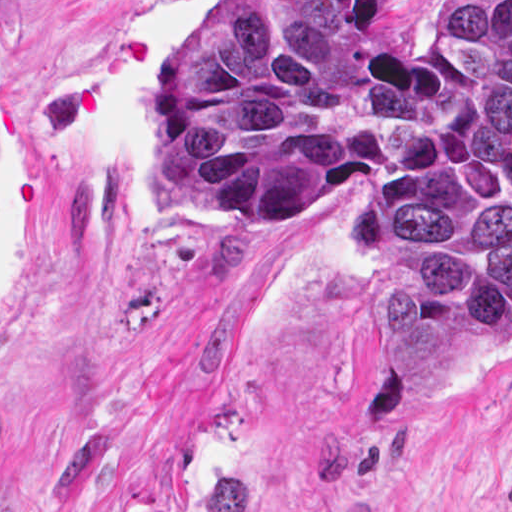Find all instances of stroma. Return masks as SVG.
Instances as JSON below:
<instances>
[{"mask_svg": "<svg viewBox=\"0 0 512 512\" xmlns=\"http://www.w3.org/2000/svg\"><path fill=\"white\" fill-rule=\"evenodd\" d=\"M228 1L0 0V512H511L512 344L448 387L361 295L369 179L215 226L156 164L187 25Z\"/></svg>", "mask_w": 512, "mask_h": 512, "instance_id": "stroma-1", "label": "stroma"}]
</instances>
